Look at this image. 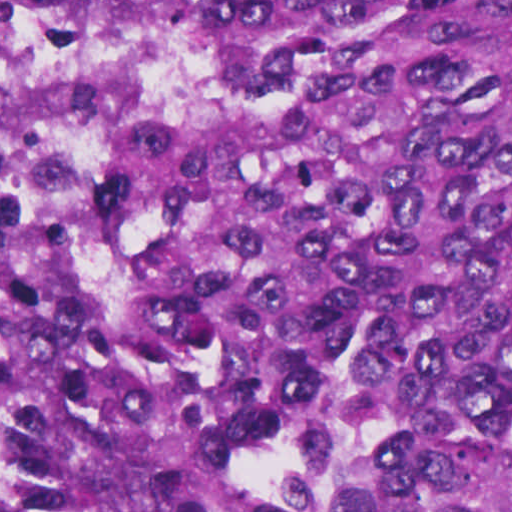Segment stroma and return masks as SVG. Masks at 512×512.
<instances>
[{
	"label": "stroma",
	"mask_w": 512,
	"mask_h": 512,
	"mask_svg": "<svg viewBox=\"0 0 512 512\" xmlns=\"http://www.w3.org/2000/svg\"><path fill=\"white\" fill-rule=\"evenodd\" d=\"M0 1H512V0H0ZM160 113L206 132H235L248 113L224 104L204 83L198 55L149 114ZM101 160L67 193L58 211L81 227L93 255L103 310H127L97 236L92 183Z\"/></svg>",
	"instance_id": "stroma-1"
}]
</instances>
